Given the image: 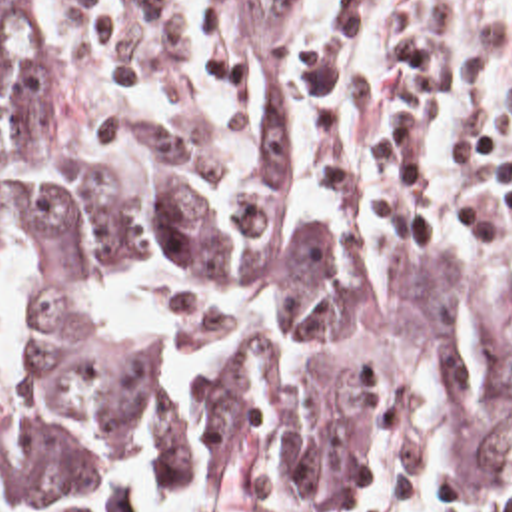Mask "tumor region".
I'll use <instances>...</instances> for the list:
<instances>
[{
  "mask_svg": "<svg viewBox=\"0 0 512 512\" xmlns=\"http://www.w3.org/2000/svg\"><path fill=\"white\" fill-rule=\"evenodd\" d=\"M241 135L101 109L83 87L67 0H0V259L141 253L245 295L213 387L103 347L67 301L27 337L77 363L49 415L0 393V512H221L359 498L379 397L453 387L465 482L512 492V297L419 249L313 217L291 179V65L309 0H235Z\"/></svg>",
  "mask_w": 512,
  "mask_h": 512,
  "instance_id": "tumor-region-1",
  "label": "tumor region"
}]
</instances>
